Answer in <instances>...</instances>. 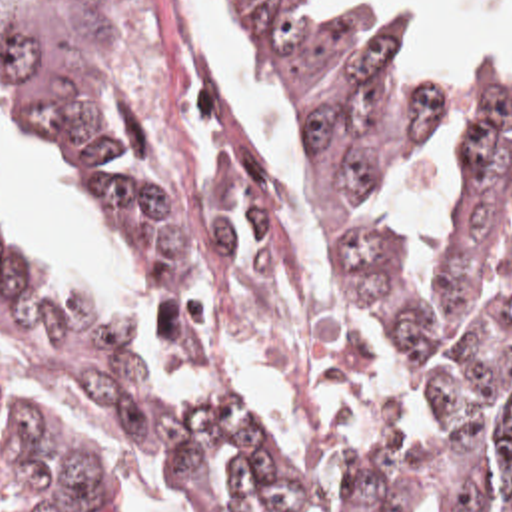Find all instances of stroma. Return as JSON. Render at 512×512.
Here are the masks:
<instances>
[{
  "label": "stroma",
  "mask_w": 512,
  "mask_h": 512,
  "mask_svg": "<svg viewBox=\"0 0 512 512\" xmlns=\"http://www.w3.org/2000/svg\"><path fill=\"white\" fill-rule=\"evenodd\" d=\"M103 1L115 11L119 25V75L133 129L155 163L219 207L223 227L233 239V303L253 333L291 369L303 407L319 387L371 371L373 347L361 335L331 325L303 301L291 273V237L277 207L271 165L251 133L247 131L237 145L205 153H189L173 141L161 97L137 67L131 31L117 0ZM351 295L357 309L385 333L365 301L353 291ZM83 313L79 299L45 297L31 327L12 335L0 333V424L14 415L2 401V387L8 385L39 383L69 403L65 347ZM407 363L411 365L409 359ZM411 369L421 383L417 369L413 365ZM47 422L89 454L109 500L101 468L85 442L67 428ZM309 426L327 454L361 470L391 466L411 446L409 442L397 450H369L311 421Z\"/></svg>",
  "instance_id": "stroma-1"
}]
</instances>
